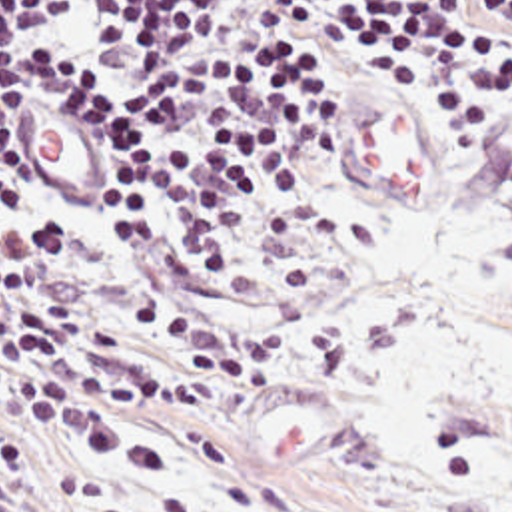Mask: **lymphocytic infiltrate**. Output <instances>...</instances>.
<instances>
[{"instance_id":"lymphocytic-infiltrate-1","label":"lymphocytic infiltrate","mask_w":512,"mask_h":512,"mask_svg":"<svg viewBox=\"0 0 512 512\" xmlns=\"http://www.w3.org/2000/svg\"><path fill=\"white\" fill-rule=\"evenodd\" d=\"M316 47L410 89L512 83V0H0L1 400L103 432L149 400L139 348L205 372L233 344L213 309L253 299L334 125ZM41 99L101 137V203L19 179Z\"/></svg>"}]
</instances>
